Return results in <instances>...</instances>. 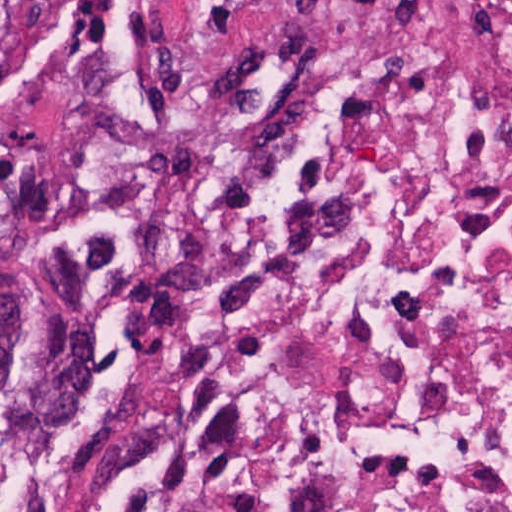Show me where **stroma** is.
I'll use <instances>...</instances> for the list:
<instances>
[{
    "instance_id": "stroma-1",
    "label": "stroma",
    "mask_w": 512,
    "mask_h": 512,
    "mask_svg": "<svg viewBox=\"0 0 512 512\" xmlns=\"http://www.w3.org/2000/svg\"><path fill=\"white\" fill-rule=\"evenodd\" d=\"M32 71L0 89V244L25 371L0 382V488L115 423L232 232L201 105L256 0H25Z\"/></svg>"
}]
</instances>
